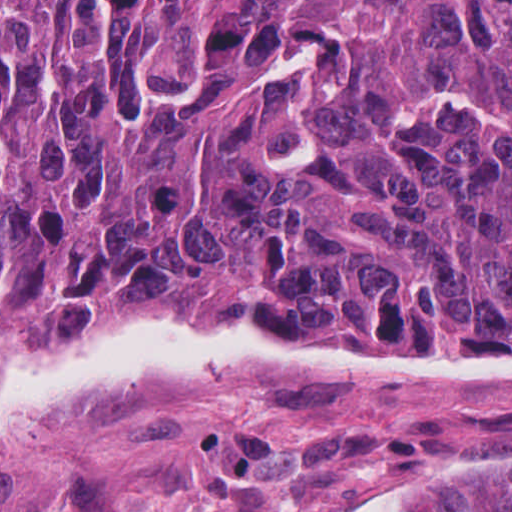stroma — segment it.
Wrapping results in <instances>:
<instances>
[{"mask_svg": "<svg viewBox=\"0 0 512 512\" xmlns=\"http://www.w3.org/2000/svg\"><path fill=\"white\" fill-rule=\"evenodd\" d=\"M0 321L248 346L45 313ZM401 350L512 361V338ZM455 470L512 471V381L156 384L1 439L0 512H397Z\"/></svg>", "mask_w": 512, "mask_h": 512, "instance_id": "obj_1", "label": "stroma"}]
</instances>
